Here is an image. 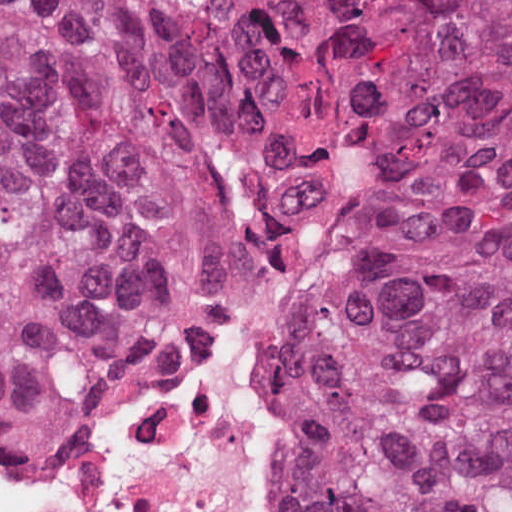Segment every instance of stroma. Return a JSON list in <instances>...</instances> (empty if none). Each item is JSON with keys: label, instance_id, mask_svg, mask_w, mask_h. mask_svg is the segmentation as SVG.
<instances>
[{"label": "stroma", "instance_id": "1", "mask_svg": "<svg viewBox=\"0 0 512 512\" xmlns=\"http://www.w3.org/2000/svg\"><path fill=\"white\" fill-rule=\"evenodd\" d=\"M367 148H368V146H367ZM367 148H365L361 152L357 153L356 155H354L353 157L348 159L337 170V172L323 185V187L316 193V195L310 200V202L308 204H306L304 210L302 211L301 215L298 218V220H300L304 215H306L314 210H325L326 213L329 215V217L332 220L330 232L321 247V250L319 252L316 263L314 265L309 283L311 282L312 278L314 277V275L316 274V272L320 266L322 258L324 256L327 246L329 244L330 238H331V236H332V234H333V232H334V230H335V228L345 210V206H346V203L348 200L351 185L354 181V178L359 169V166L367 152ZM309 283H308V285H309ZM308 285L303 290L301 295L296 299V301L286 311L285 315L283 316V318L280 322L278 330H277L275 336L273 337V339L271 340V342L277 337V335L283 330V328L287 325V323L290 321V319L296 313V309H297ZM263 360H264V356H263ZM262 368H263V361H262ZM261 386H262L268 400L270 401L271 405L276 410V412L280 415V442H281L285 438V429H284V424H283L282 415H281V403L265 391L262 369H261ZM283 445H285V439L281 446H283ZM276 508H277L278 512H287L285 506L283 505L282 501L280 500V498L277 494V489H276Z\"/></svg>", "mask_w": 512, "mask_h": 512}]
</instances>
